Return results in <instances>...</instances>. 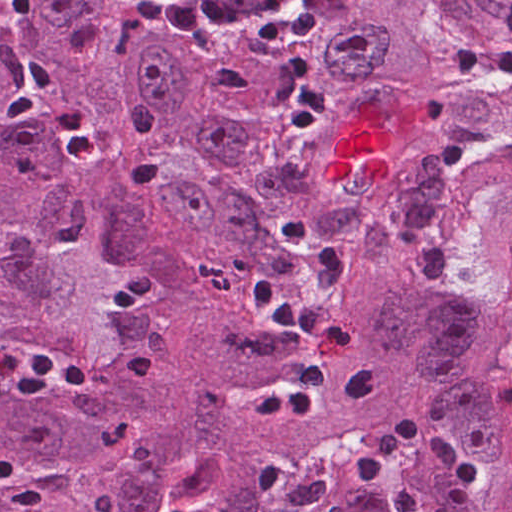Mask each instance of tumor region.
I'll use <instances>...</instances> for the list:
<instances>
[{"label":"tumor region","mask_w":512,"mask_h":512,"mask_svg":"<svg viewBox=\"0 0 512 512\" xmlns=\"http://www.w3.org/2000/svg\"><path fill=\"white\" fill-rule=\"evenodd\" d=\"M349 336L307 416L257 419ZM0 512H512V0H347L314 39L177 49L115 0L0 15ZM406 443L342 475L391 414ZM312 447L308 454L303 457Z\"/></svg>","instance_id":"1"}]
</instances>
